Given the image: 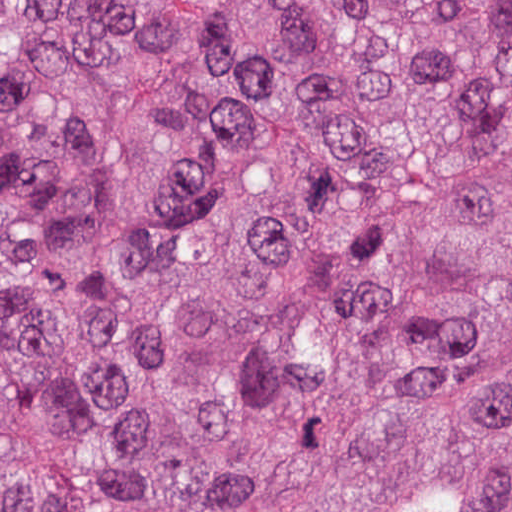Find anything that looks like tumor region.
Returning <instances> with one entry per match:
<instances>
[{"instance_id":"tumor-region-1","label":"tumor region","mask_w":512,"mask_h":512,"mask_svg":"<svg viewBox=\"0 0 512 512\" xmlns=\"http://www.w3.org/2000/svg\"><path fill=\"white\" fill-rule=\"evenodd\" d=\"M0 512H512V0H0Z\"/></svg>"}]
</instances>
